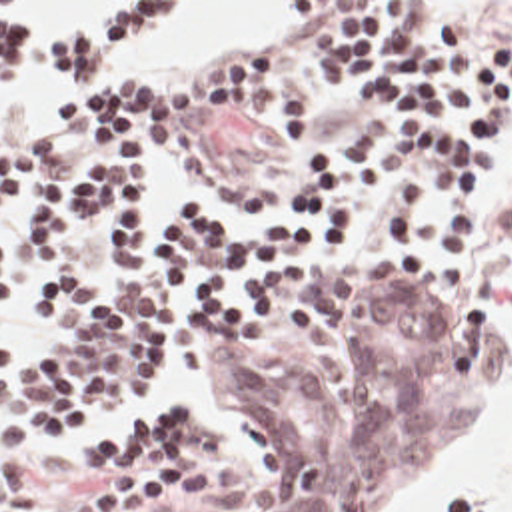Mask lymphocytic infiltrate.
<instances>
[{
  "label": "lymphocytic infiltrate",
  "mask_w": 512,
  "mask_h": 512,
  "mask_svg": "<svg viewBox=\"0 0 512 512\" xmlns=\"http://www.w3.org/2000/svg\"><path fill=\"white\" fill-rule=\"evenodd\" d=\"M172 4L114 2L72 34H36L0 2V96L24 70L68 84L52 130L0 132V206L30 204L26 234L56 264L36 282L32 343L12 351L0 331V423L14 433L144 423L182 375V333L244 339L290 282L344 266L469 280L481 258L491 126L512 118V44L471 42L442 2H304L312 72L360 88L372 118L354 148L304 160L290 208L220 220L186 200L152 202L124 160L168 148L184 120L300 128L316 116V92L292 86L266 50L198 62L180 78L88 84L132 58ZM96 238L124 270L118 298L80 260ZM0 304H12L2 242ZM0 512L54 511L18 477L0 483Z\"/></svg>",
  "instance_id": "1"
}]
</instances>
